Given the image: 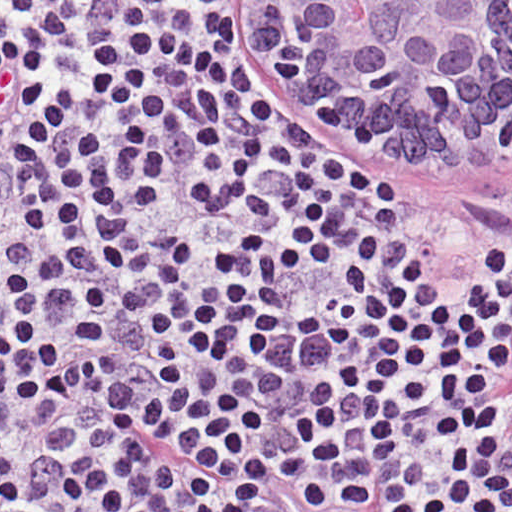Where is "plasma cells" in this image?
Masks as SVG:
<instances>
[{
    "mask_svg": "<svg viewBox=\"0 0 512 512\" xmlns=\"http://www.w3.org/2000/svg\"><path fill=\"white\" fill-rule=\"evenodd\" d=\"M324 410L318 389L297 387L249 396L213 412L210 424L242 480L300 494L320 512H486L498 445L411 419L330 439Z\"/></svg>",
    "mask_w": 512,
    "mask_h": 512,
    "instance_id": "plasma-cells-1",
    "label": "plasma cells"
}]
</instances>
